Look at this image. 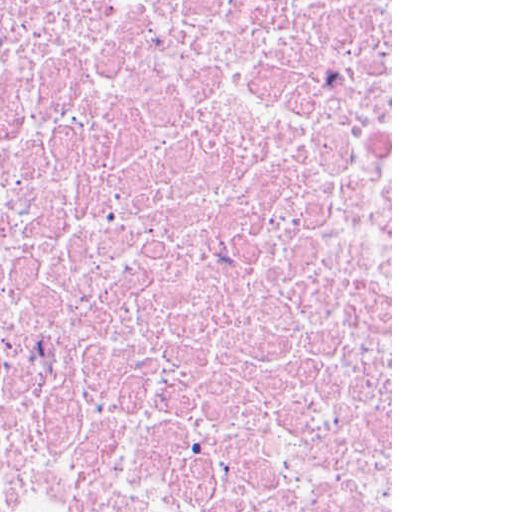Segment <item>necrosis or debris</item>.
Segmentation results:
<instances>
[{"instance_id": "obj_1", "label": "necrosis or debris", "mask_w": 512, "mask_h": 512, "mask_svg": "<svg viewBox=\"0 0 512 512\" xmlns=\"http://www.w3.org/2000/svg\"><path fill=\"white\" fill-rule=\"evenodd\" d=\"M0 512H391V0H0Z\"/></svg>"}]
</instances>
